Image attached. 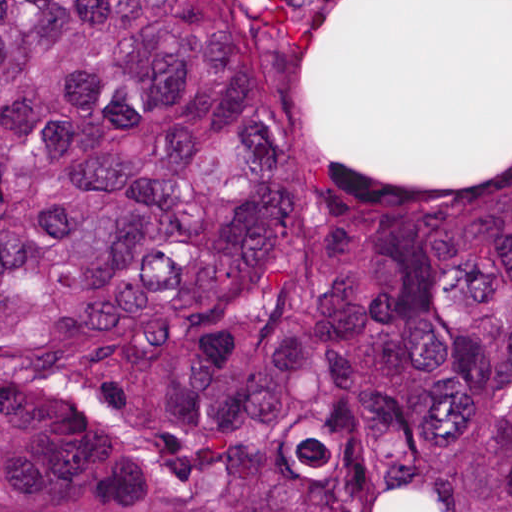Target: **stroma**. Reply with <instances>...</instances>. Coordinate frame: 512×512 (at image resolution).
Returning a JSON list of instances; mask_svg holds the SVG:
<instances>
[{
    "label": "stroma",
    "mask_w": 512,
    "mask_h": 512,
    "mask_svg": "<svg viewBox=\"0 0 512 512\" xmlns=\"http://www.w3.org/2000/svg\"><path fill=\"white\" fill-rule=\"evenodd\" d=\"M243 1L304 151L499 155L512 0Z\"/></svg>",
    "instance_id": "35a3bbf8"
}]
</instances>
